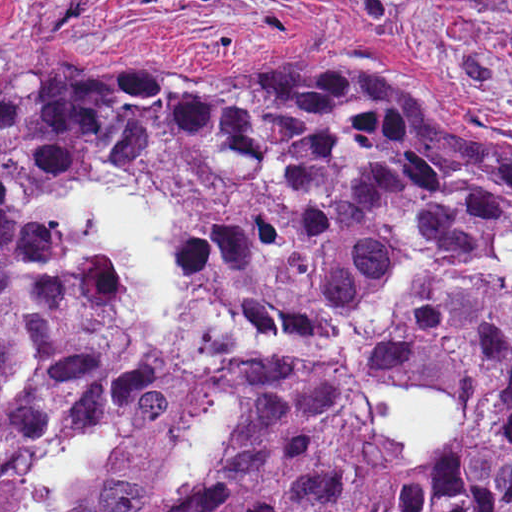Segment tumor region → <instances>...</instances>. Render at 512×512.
<instances>
[{"label":"tumor region","instance_id":"obj_1","mask_svg":"<svg viewBox=\"0 0 512 512\" xmlns=\"http://www.w3.org/2000/svg\"><path fill=\"white\" fill-rule=\"evenodd\" d=\"M86 179L164 206L213 334L197 363L119 314V256L39 210ZM200 227V228H199ZM0 512L113 419L61 512H512V161L382 66L0 79ZM474 402L424 462L364 406L377 370ZM235 428L171 486L215 396Z\"/></svg>","mask_w":512,"mask_h":512}]
</instances>
